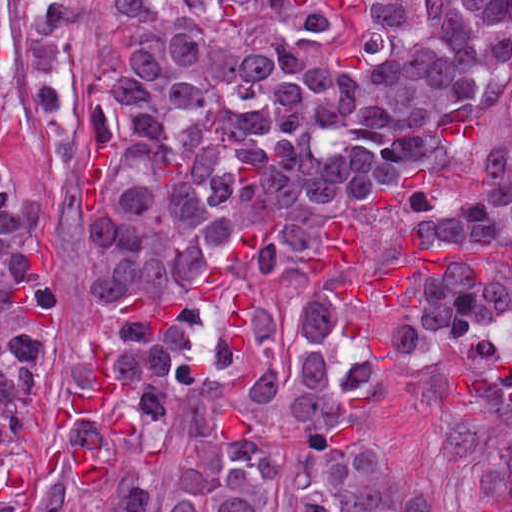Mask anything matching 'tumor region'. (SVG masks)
<instances>
[{"label": "tumor region", "mask_w": 512, "mask_h": 512, "mask_svg": "<svg viewBox=\"0 0 512 512\" xmlns=\"http://www.w3.org/2000/svg\"><path fill=\"white\" fill-rule=\"evenodd\" d=\"M86 0H21L38 114L76 93ZM75 195L94 269L55 448L110 512H141L170 432L192 431L173 512H436L393 459L371 389L501 294L512 264V0H111ZM1 4V0H0ZM13 110L0 11V136ZM346 216L375 261L427 244L494 253L420 272L409 307H358L302 270ZM56 255L35 198L0 185V512L24 493L22 427L53 353ZM108 349L116 439L51 419Z\"/></svg>", "instance_id": "1"}]
</instances>
